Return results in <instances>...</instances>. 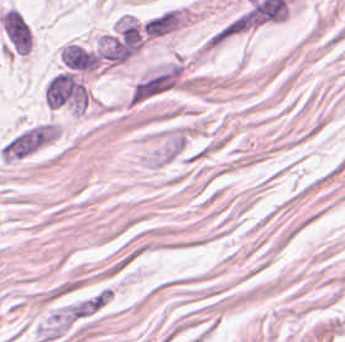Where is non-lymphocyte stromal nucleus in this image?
<instances>
[{
    "label": "non-lymphocyte stromal nucleus",
    "mask_w": 345,
    "mask_h": 342,
    "mask_svg": "<svg viewBox=\"0 0 345 342\" xmlns=\"http://www.w3.org/2000/svg\"><path fill=\"white\" fill-rule=\"evenodd\" d=\"M188 91L191 77L185 59L168 58L140 71L124 100L129 108H137Z\"/></svg>",
    "instance_id": "obj_1"
},
{
    "label": "non-lymphocyte stromal nucleus",
    "mask_w": 345,
    "mask_h": 342,
    "mask_svg": "<svg viewBox=\"0 0 345 342\" xmlns=\"http://www.w3.org/2000/svg\"><path fill=\"white\" fill-rule=\"evenodd\" d=\"M61 135L28 122L12 132L0 161L17 162L60 156Z\"/></svg>",
    "instance_id": "obj_2"
}]
</instances>
